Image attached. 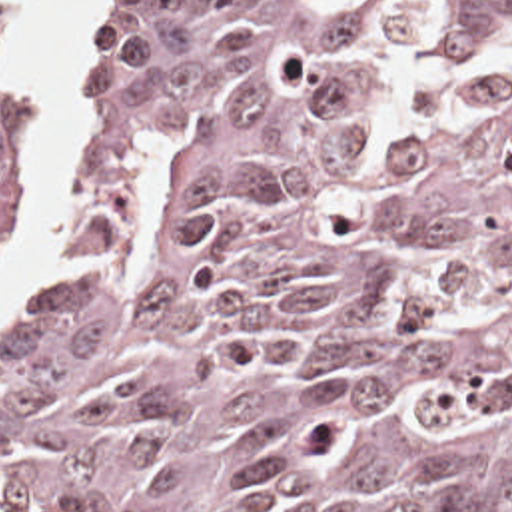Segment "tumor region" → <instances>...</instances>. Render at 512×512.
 I'll return each mask as SVG.
<instances>
[{
  "instance_id": "obj_1",
  "label": "tumor region",
  "mask_w": 512,
  "mask_h": 512,
  "mask_svg": "<svg viewBox=\"0 0 512 512\" xmlns=\"http://www.w3.org/2000/svg\"><path fill=\"white\" fill-rule=\"evenodd\" d=\"M512 0H151L0 338V512H512ZM41 94L0 6V260Z\"/></svg>"
}]
</instances>
